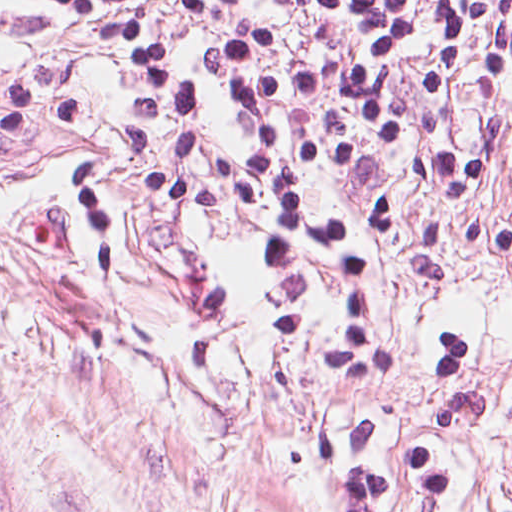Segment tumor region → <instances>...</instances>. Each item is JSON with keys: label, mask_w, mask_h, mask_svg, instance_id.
<instances>
[{"label": "tumor region", "mask_w": 512, "mask_h": 512, "mask_svg": "<svg viewBox=\"0 0 512 512\" xmlns=\"http://www.w3.org/2000/svg\"><path fill=\"white\" fill-rule=\"evenodd\" d=\"M0 512H30L16 492L0 476Z\"/></svg>", "instance_id": "1"}]
</instances>
